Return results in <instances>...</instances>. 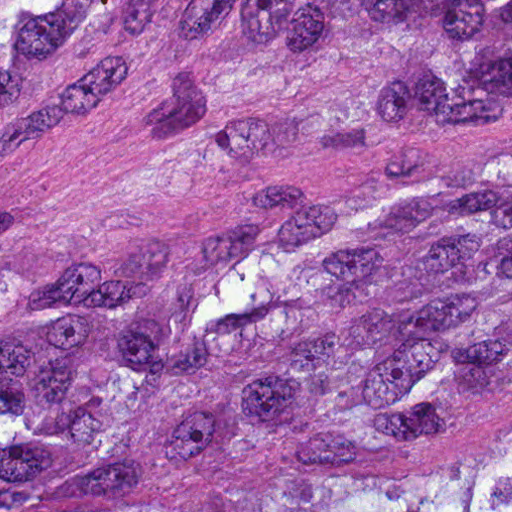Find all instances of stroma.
<instances>
[{
    "instance_id": "1",
    "label": "stroma",
    "mask_w": 512,
    "mask_h": 512,
    "mask_svg": "<svg viewBox=\"0 0 512 512\" xmlns=\"http://www.w3.org/2000/svg\"><path fill=\"white\" fill-rule=\"evenodd\" d=\"M153 97L92 129L0 153V247L194 232L266 190L333 191L367 165L361 148L305 165L208 162L142 137Z\"/></svg>"
}]
</instances>
